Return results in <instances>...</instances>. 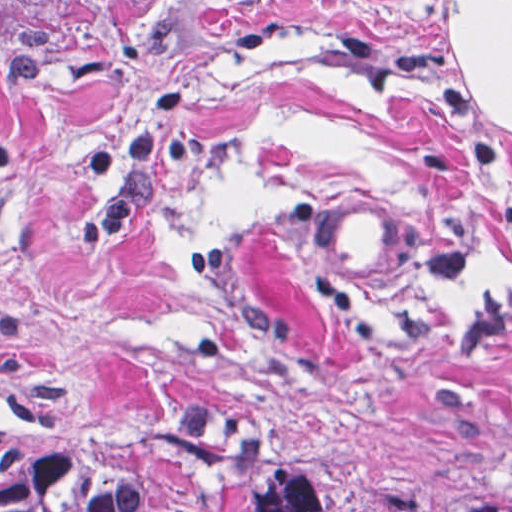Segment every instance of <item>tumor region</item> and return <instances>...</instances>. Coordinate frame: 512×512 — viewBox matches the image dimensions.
Masks as SVG:
<instances>
[{
	"mask_svg": "<svg viewBox=\"0 0 512 512\" xmlns=\"http://www.w3.org/2000/svg\"><path fill=\"white\" fill-rule=\"evenodd\" d=\"M78 0H0V49L62 22ZM0 512H394L291 461L240 424H122L0 440ZM512 512V511H510Z\"/></svg>",
	"mask_w": 512,
	"mask_h": 512,
	"instance_id": "tumor-region-1",
	"label": "tumor region"
}]
</instances>
